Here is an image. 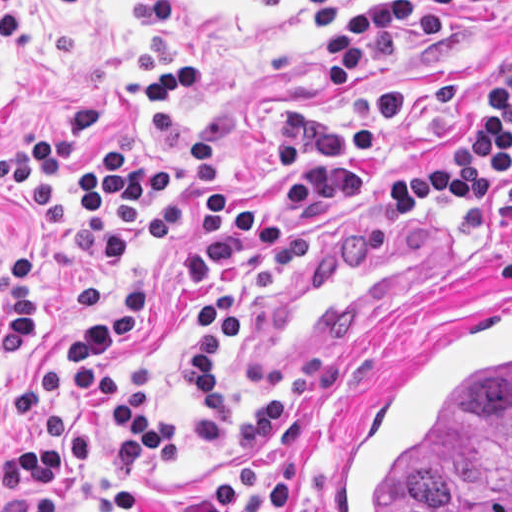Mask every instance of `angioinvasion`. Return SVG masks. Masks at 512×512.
I'll list each match as a JSON object with an SVG mask.
<instances>
[{
  "mask_svg": "<svg viewBox=\"0 0 512 512\" xmlns=\"http://www.w3.org/2000/svg\"><path fill=\"white\" fill-rule=\"evenodd\" d=\"M333 512H512V301L414 348L347 451Z\"/></svg>",
  "mask_w": 512,
  "mask_h": 512,
  "instance_id": "1",
  "label": "angioinvasion"
}]
</instances>
